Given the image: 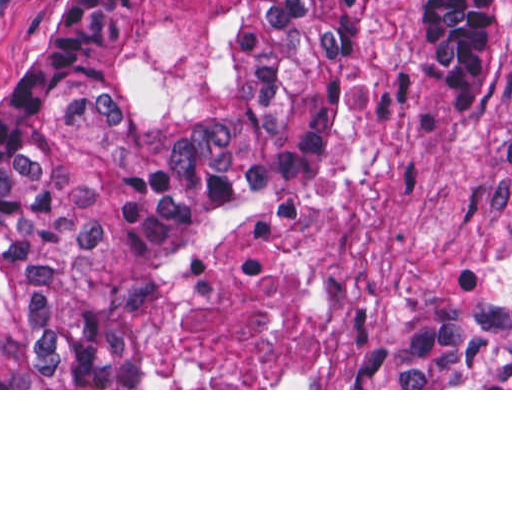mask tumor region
Segmentation results:
<instances>
[{
	"mask_svg": "<svg viewBox=\"0 0 512 512\" xmlns=\"http://www.w3.org/2000/svg\"><path fill=\"white\" fill-rule=\"evenodd\" d=\"M360 0H69L0 76V388H145L178 247L304 181ZM456 102L496 0H429ZM366 388H512V302L410 303Z\"/></svg>",
	"mask_w": 512,
	"mask_h": 512,
	"instance_id": "1",
	"label": "tumor region"
}]
</instances>
